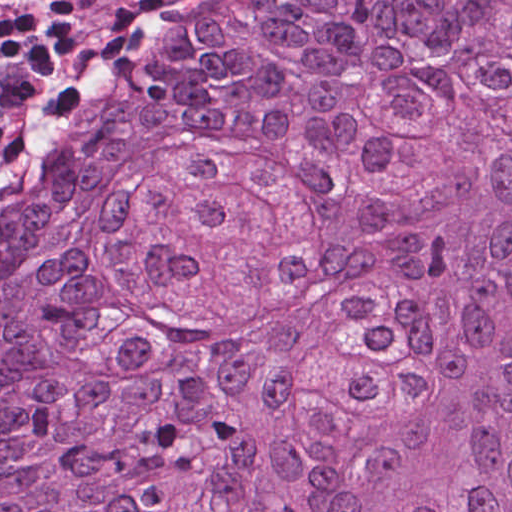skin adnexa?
<instances>
[{
  "instance_id": "skin-adnexa-1",
  "label": "skin adnexa",
  "mask_w": 512,
  "mask_h": 512,
  "mask_svg": "<svg viewBox=\"0 0 512 512\" xmlns=\"http://www.w3.org/2000/svg\"><path fill=\"white\" fill-rule=\"evenodd\" d=\"M0 238V512H512V0H195Z\"/></svg>"
}]
</instances>
